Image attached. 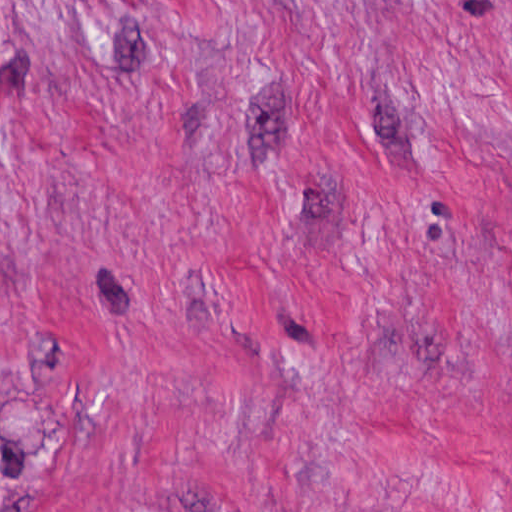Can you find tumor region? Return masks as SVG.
Instances as JSON below:
<instances>
[{"label": "tumor region", "mask_w": 512, "mask_h": 512, "mask_svg": "<svg viewBox=\"0 0 512 512\" xmlns=\"http://www.w3.org/2000/svg\"><path fill=\"white\" fill-rule=\"evenodd\" d=\"M0 404V490L13 491L23 472L43 464V425L24 402Z\"/></svg>", "instance_id": "tumor-region-1"}]
</instances>
